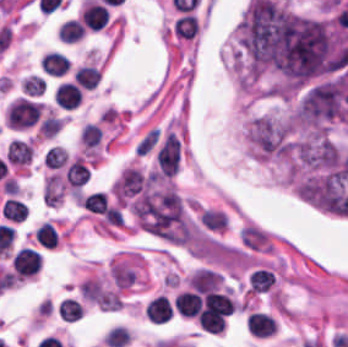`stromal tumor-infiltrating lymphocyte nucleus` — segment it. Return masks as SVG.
<instances>
[{
	"mask_svg": "<svg viewBox=\"0 0 348 347\" xmlns=\"http://www.w3.org/2000/svg\"><path fill=\"white\" fill-rule=\"evenodd\" d=\"M41 108L42 104L21 97L8 106L5 121L9 128L26 129L37 121Z\"/></svg>",
	"mask_w": 348,
	"mask_h": 347,
	"instance_id": "stromal-tumor-infiltrating-lymphocyte-nucleus-1",
	"label": "stromal tumor-infiltrating lymphocyte nucleus"
},
{
	"mask_svg": "<svg viewBox=\"0 0 348 347\" xmlns=\"http://www.w3.org/2000/svg\"><path fill=\"white\" fill-rule=\"evenodd\" d=\"M108 11L103 3L84 0L80 10V22L91 31H98L107 24Z\"/></svg>",
	"mask_w": 348,
	"mask_h": 347,
	"instance_id": "stromal-tumor-infiltrating-lymphocyte-nucleus-2",
	"label": "stromal tumor-infiltrating lymphocyte nucleus"
},
{
	"mask_svg": "<svg viewBox=\"0 0 348 347\" xmlns=\"http://www.w3.org/2000/svg\"><path fill=\"white\" fill-rule=\"evenodd\" d=\"M41 268V257L37 251L21 247L13 256L16 277H29Z\"/></svg>",
	"mask_w": 348,
	"mask_h": 347,
	"instance_id": "stromal-tumor-infiltrating-lymphocyte-nucleus-3",
	"label": "stromal tumor-infiltrating lymphocyte nucleus"
},
{
	"mask_svg": "<svg viewBox=\"0 0 348 347\" xmlns=\"http://www.w3.org/2000/svg\"><path fill=\"white\" fill-rule=\"evenodd\" d=\"M246 330L253 336L266 338L273 336L278 328L273 316L254 311L247 316Z\"/></svg>",
	"mask_w": 348,
	"mask_h": 347,
	"instance_id": "stromal-tumor-infiltrating-lymphocyte-nucleus-4",
	"label": "stromal tumor-infiltrating lymphocyte nucleus"
},
{
	"mask_svg": "<svg viewBox=\"0 0 348 347\" xmlns=\"http://www.w3.org/2000/svg\"><path fill=\"white\" fill-rule=\"evenodd\" d=\"M70 68V60L63 54L47 51L42 58L41 69L49 77H63Z\"/></svg>",
	"mask_w": 348,
	"mask_h": 347,
	"instance_id": "stromal-tumor-infiltrating-lymphocyte-nucleus-5",
	"label": "stromal tumor-infiltrating lymphocyte nucleus"
},
{
	"mask_svg": "<svg viewBox=\"0 0 348 347\" xmlns=\"http://www.w3.org/2000/svg\"><path fill=\"white\" fill-rule=\"evenodd\" d=\"M55 100L63 109H76L82 99V90L74 83L62 82L54 94Z\"/></svg>",
	"mask_w": 348,
	"mask_h": 347,
	"instance_id": "stromal-tumor-infiltrating-lymphocyte-nucleus-6",
	"label": "stromal tumor-infiltrating lymphocyte nucleus"
},
{
	"mask_svg": "<svg viewBox=\"0 0 348 347\" xmlns=\"http://www.w3.org/2000/svg\"><path fill=\"white\" fill-rule=\"evenodd\" d=\"M65 180L76 192L87 182V164L84 157L75 156L68 164Z\"/></svg>",
	"mask_w": 348,
	"mask_h": 347,
	"instance_id": "stromal-tumor-infiltrating-lymphocyte-nucleus-7",
	"label": "stromal tumor-infiltrating lymphocyte nucleus"
},
{
	"mask_svg": "<svg viewBox=\"0 0 348 347\" xmlns=\"http://www.w3.org/2000/svg\"><path fill=\"white\" fill-rule=\"evenodd\" d=\"M172 29L176 37L184 40H192L199 30V22L196 15L184 13L175 19Z\"/></svg>",
	"mask_w": 348,
	"mask_h": 347,
	"instance_id": "stromal-tumor-infiltrating-lymphocyte-nucleus-8",
	"label": "stromal tumor-infiltrating lymphocyte nucleus"
},
{
	"mask_svg": "<svg viewBox=\"0 0 348 347\" xmlns=\"http://www.w3.org/2000/svg\"><path fill=\"white\" fill-rule=\"evenodd\" d=\"M173 309L168 300L162 296L153 298L147 305L145 316L151 322H165Z\"/></svg>",
	"mask_w": 348,
	"mask_h": 347,
	"instance_id": "stromal-tumor-infiltrating-lymphocyte-nucleus-9",
	"label": "stromal tumor-infiltrating lymphocyte nucleus"
},
{
	"mask_svg": "<svg viewBox=\"0 0 348 347\" xmlns=\"http://www.w3.org/2000/svg\"><path fill=\"white\" fill-rule=\"evenodd\" d=\"M32 149L26 141L13 139L8 143L5 156L11 164L23 165L31 161Z\"/></svg>",
	"mask_w": 348,
	"mask_h": 347,
	"instance_id": "stromal-tumor-infiltrating-lymphocyte-nucleus-10",
	"label": "stromal tumor-infiltrating lymphocyte nucleus"
},
{
	"mask_svg": "<svg viewBox=\"0 0 348 347\" xmlns=\"http://www.w3.org/2000/svg\"><path fill=\"white\" fill-rule=\"evenodd\" d=\"M80 89L93 90L101 78V72L90 65L80 66L73 76Z\"/></svg>",
	"mask_w": 348,
	"mask_h": 347,
	"instance_id": "stromal-tumor-infiltrating-lymphocyte-nucleus-11",
	"label": "stromal tumor-infiltrating lymphocyte nucleus"
},
{
	"mask_svg": "<svg viewBox=\"0 0 348 347\" xmlns=\"http://www.w3.org/2000/svg\"><path fill=\"white\" fill-rule=\"evenodd\" d=\"M0 214L13 223H21L26 219L27 209L15 198H8L0 207Z\"/></svg>",
	"mask_w": 348,
	"mask_h": 347,
	"instance_id": "stromal-tumor-infiltrating-lymphocyte-nucleus-12",
	"label": "stromal tumor-infiltrating lymphocyte nucleus"
},
{
	"mask_svg": "<svg viewBox=\"0 0 348 347\" xmlns=\"http://www.w3.org/2000/svg\"><path fill=\"white\" fill-rule=\"evenodd\" d=\"M200 305V295L194 292H181L176 303V311L186 317H194Z\"/></svg>",
	"mask_w": 348,
	"mask_h": 347,
	"instance_id": "stromal-tumor-infiltrating-lymphocyte-nucleus-13",
	"label": "stromal tumor-infiltrating lymphocyte nucleus"
},
{
	"mask_svg": "<svg viewBox=\"0 0 348 347\" xmlns=\"http://www.w3.org/2000/svg\"><path fill=\"white\" fill-rule=\"evenodd\" d=\"M38 245L47 249H55L58 246V233L53 224L43 222L35 230Z\"/></svg>",
	"mask_w": 348,
	"mask_h": 347,
	"instance_id": "stromal-tumor-infiltrating-lymphocyte-nucleus-14",
	"label": "stromal tumor-infiltrating lymphocyte nucleus"
},
{
	"mask_svg": "<svg viewBox=\"0 0 348 347\" xmlns=\"http://www.w3.org/2000/svg\"><path fill=\"white\" fill-rule=\"evenodd\" d=\"M58 312L65 321L76 322L82 319L84 309L82 303L77 300L64 298L60 302Z\"/></svg>",
	"mask_w": 348,
	"mask_h": 347,
	"instance_id": "stromal-tumor-infiltrating-lymphocyte-nucleus-15",
	"label": "stromal tumor-infiltrating lymphocyte nucleus"
},
{
	"mask_svg": "<svg viewBox=\"0 0 348 347\" xmlns=\"http://www.w3.org/2000/svg\"><path fill=\"white\" fill-rule=\"evenodd\" d=\"M86 29L80 20L69 19L62 23L58 33V39L65 42H76L81 38Z\"/></svg>",
	"mask_w": 348,
	"mask_h": 347,
	"instance_id": "stromal-tumor-infiltrating-lymphocyte-nucleus-16",
	"label": "stromal tumor-infiltrating lymphocyte nucleus"
},
{
	"mask_svg": "<svg viewBox=\"0 0 348 347\" xmlns=\"http://www.w3.org/2000/svg\"><path fill=\"white\" fill-rule=\"evenodd\" d=\"M81 207L94 214H103L107 210V200L102 191H95L83 198Z\"/></svg>",
	"mask_w": 348,
	"mask_h": 347,
	"instance_id": "stromal-tumor-infiltrating-lymphocyte-nucleus-17",
	"label": "stromal tumor-infiltrating lymphocyte nucleus"
},
{
	"mask_svg": "<svg viewBox=\"0 0 348 347\" xmlns=\"http://www.w3.org/2000/svg\"><path fill=\"white\" fill-rule=\"evenodd\" d=\"M128 340V329L122 326H114L105 333L102 342L108 347H123Z\"/></svg>",
	"mask_w": 348,
	"mask_h": 347,
	"instance_id": "stromal-tumor-infiltrating-lymphocyte-nucleus-18",
	"label": "stromal tumor-infiltrating lymphocyte nucleus"
}]
</instances>
